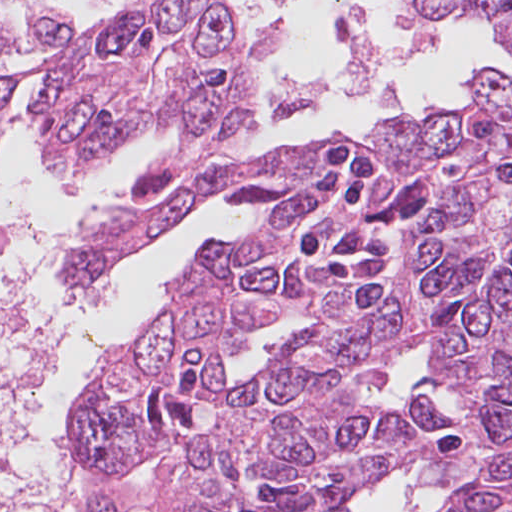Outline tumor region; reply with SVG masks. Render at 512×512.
<instances>
[{
	"instance_id": "tumor-region-1",
	"label": "tumor region",
	"mask_w": 512,
	"mask_h": 512,
	"mask_svg": "<svg viewBox=\"0 0 512 512\" xmlns=\"http://www.w3.org/2000/svg\"><path fill=\"white\" fill-rule=\"evenodd\" d=\"M460 24L512 0H405ZM244 35L38 98L43 154L82 183L150 135L175 132L139 193L74 245L66 288L94 283L221 192L252 211L164 284L147 328L111 354L83 432L102 488L158 512H346L360 487L431 454L430 486L472 474L445 512H512V78L469 77L462 110L374 123L249 156ZM10 108L0 110V143ZM425 343L459 394V422L421 397L368 395ZM432 434L458 430L439 447ZM435 489V488H432Z\"/></svg>"
}]
</instances>
